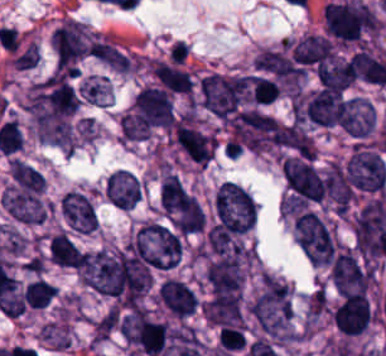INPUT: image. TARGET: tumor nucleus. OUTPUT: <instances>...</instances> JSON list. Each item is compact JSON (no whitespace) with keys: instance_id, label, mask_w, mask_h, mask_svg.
I'll list each match as a JSON object with an SVG mask.
<instances>
[{"instance_id":"1","label":"tumor nucleus","mask_w":386,"mask_h":356,"mask_svg":"<svg viewBox=\"0 0 386 356\" xmlns=\"http://www.w3.org/2000/svg\"><path fill=\"white\" fill-rule=\"evenodd\" d=\"M152 270H169L180 261L181 233L158 221H144L123 245Z\"/></svg>"},{"instance_id":"2","label":"tumor nucleus","mask_w":386,"mask_h":356,"mask_svg":"<svg viewBox=\"0 0 386 356\" xmlns=\"http://www.w3.org/2000/svg\"><path fill=\"white\" fill-rule=\"evenodd\" d=\"M296 243L310 265H330L336 252L333 235L319 217L310 209H302L293 218Z\"/></svg>"},{"instance_id":"3","label":"tumor nucleus","mask_w":386,"mask_h":356,"mask_svg":"<svg viewBox=\"0 0 386 356\" xmlns=\"http://www.w3.org/2000/svg\"><path fill=\"white\" fill-rule=\"evenodd\" d=\"M214 222L253 225L257 219L249 190L230 180H223L214 191Z\"/></svg>"},{"instance_id":"4","label":"tumor nucleus","mask_w":386,"mask_h":356,"mask_svg":"<svg viewBox=\"0 0 386 356\" xmlns=\"http://www.w3.org/2000/svg\"><path fill=\"white\" fill-rule=\"evenodd\" d=\"M160 205L176 227H202L201 206L180 179L172 173L163 179Z\"/></svg>"},{"instance_id":"5","label":"tumor nucleus","mask_w":386,"mask_h":356,"mask_svg":"<svg viewBox=\"0 0 386 356\" xmlns=\"http://www.w3.org/2000/svg\"><path fill=\"white\" fill-rule=\"evenodd\" d=\"M343 167L349 189L380 190L386 181V165L380 153L360 144Z\"/></svg>"},{"instance_id":"6","label":"tumor nucleus","mask_w":386,"mask_h":356,"mask_svg":"<svg viewBox=\"0 0 386 356\" xmlns=\"http://www.w3.org/2000/svg\"><path fill=\"white\" fill-rule=\"evenodd\" d=\"M281 169L293 195L301 199H321L326 182L306 159L287 155L281 161Z\"/></svg>"},{"instance_id":"7","label":"tumor nucleus","mask_w":386,"mask_h":356,"mask_svg":"<svg viewBox=\"0 0 386 356\" xmlns=\"http://www.w3.org/2000/svg\"><path fill=\"white\" fill-rule=\"evenodd\" d=\"M51 44L60 70L85 55L86 36L82 22L67 17L52 31Z\"/></svg>"},{"instance_id":"8","label":"tumor nucleus","mask_w":386,"mask_h":356,"mask_svg":"<svg viewBox=\"0 0 386 356\" xmlns=\"http://www.w3.org/2000/svg\"><path fill=\"white\" fill-rule=\"evenodd\" d=\"M331 279L344 294L365 290L370 271L349 247H341L330 266Z\"/></svg>"},{"instance_id":"9","label":"tumor nucleus","mask_w":386,"mask_h":356,"mask_svg":"<svg viewBox=\"0 0 386 356\" xmlns=\"http://www.w3.org/2000/svg\"><path fill=\"white\" fill-rule=\"evenodd\" d=\"M156 300L166 313L177 318H186L198 306L197 295L189 283L172 276L159 281Z\"/></svg>"},{"instance_id":"10","label":"tumor nucleus","mask_w":386,"mask_h":356,"mask_svg":"<svg viewBox=\"0 0 386 356\" xmlns=\"http://www.w3.org/2000/svg\"><path fill=\"white\" fill-rule=\"evenodd\" d=\"M333 320L345 334L363 332L371 320L368 298L360 291H348L337 303Z\"/></svg>"},{"instance_id":"11","label":"tumor nucleus","mask_w":386,"mask_h":356,"mask_svg":"<svg viewBox=\"0 0 386 356\" xmlns=\"http://www.w3.org/2000/svg\"><path fill=\"white\" fill-rule=\"evenodd\" d=\"M173 131L180 148L194 160L205 164L215 147V136L185 118L173 124Z\"/></svg>"},{"instance_id":"12","label":"tumor nucleus","mask_w":386,"mask_h":356,"mask_svg":"<svg viewBox=\"0 0 386 356\" xmlns=\"http://www.w3.org/2000/svg\"><path fill=\"white\" fill-rule=\"evenodd\" d=\"M60 209L72 228L80 232H91L95 229L96 211L84 193L67 190L61 198Z\"/></svg>"},{"instance_id":"13","label":"tumor nucleus","mask_w":386,"mask_h":356,"mask_svg":"<svg viewBox=\"0 0 386 356\" xmlns=\"http://www.w3.org/2000/svg\"><path fill=\"white\" fill-rule=\"evenodd\" d=\"M140 188L132 171L118 168L104 182L108 202L120 209H129L139 196Z\"/></svg>"},{"instance_id":"14","label":"tumor nucleus","mask_w":386,"mask_h":356,"mask_svg":"<svg viewBox=\"0 0 386 356\" xmlns=\"http://www.w3.org/2000/svg\"><path fill=\"white\" fill-rule=\"evenodd\" d=\"M375 122L374 106L361 94L349 97L343 128L351 136H366Z\"/></svg>"},{"instance_id":"15","label":"tumor nucleus","mask_w":386,"mask_h":356,"mask_svg":"<svg viewBox=\"0 0 386 356\" xmlns=\"http://www.w3.org/2000/svg\"><path fill=\"white\" fill-rule=\"evenodd\" d=\"M293 60L312 64L332 58V43L320 35L306 34L291 45Z\"/></svg>"},{"instance_id":"16","label":"tumor nucleus","mask_w":386,"mask_h":356,"mask_svg":"<svg viewBox=\"0 0 386 356\" xmlns=\"http://www.w3.org/2000/svg\"><path fill=\"white\" fill-rule=\"evenodd\" d=\"M80 247L67 232H54L47 241L48 261L55 266L76 268Z\"/></svg>"},{"instance_id":"17","label":"tumor nucleus","mask_w":386,"mask_h":356,"mask_svg":"<svg viewBox=\"0 0 386 356\" xmlns=\"http://www.w3.org/2000/svg\"><path fill=\"white\" fill-rule=\"evenodd\" d=\"M148 65L155 78L171 92L191 93L192 81L180 67L152 58Z\"/></svg>"},{"instance_id":"18","label":"tumor nucleus","mask_w":386,"mask_h":356,"mask_svg":"<svg viewBox=\"0 0 386 356\" xmlns=\"http://www.w3.org/2000/svg\"><path fill=\"white\" fill-rule=\"evenodd\" d=\"M317 70L324 88L344 89L355 79L350 59L336 57L320 63Z\"/></svg>"},{"instance_id":"19","label":"tumor nucleus","mask_w":386,"mask_h":356,"mask_svg":"<svg viewBox=\"0 0 386 356\" xmlns=\"http://www.w3.org/2000/svg\"><path fill=\"white\" fill-rule=\"evenodd\" d=\"M273 142L304 155L312 153L311 135L295 123L278 125L273 130Z\"/></svg>"},{"instance_id":"20","label":"tumor nucleus","mask_w":386,"mask_h":356,"mask_svg":"<svg viewBox=\"0 0 386 356\" xmlns=\"http://www.w3.org/2000/svg\"><path fill=\"white\" fill-rule=\"evenodd\" d=\"M89 53L117 70H128L130 58L113 43L106 40H93L86 46Z\"/></svg>"},{"instance_id":"21","label":"tumor nucleus","mask_w":386,"mask_h":356,"mask_svg":"<svg viewBox=\"0 0 386 356\" xmlns=\"http://www.w3.org/2000/svg\"><path fill=\"white\" fill-rule=\"evenodd\" d=\"M56 287L43 277L28 282L22 292V300L35 308H42L53 297Z\"/></svg>"}]
</instances>
